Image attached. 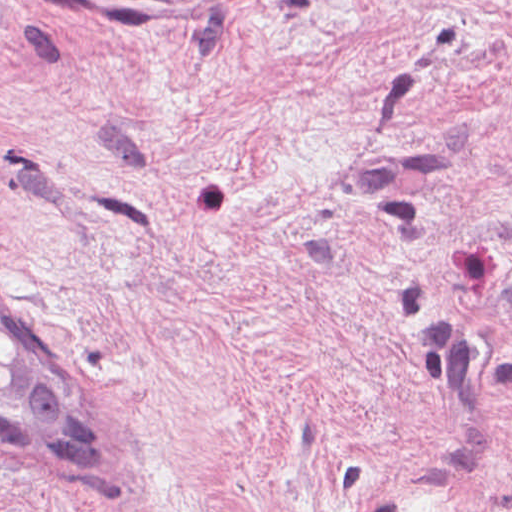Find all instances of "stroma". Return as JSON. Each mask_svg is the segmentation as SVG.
Returning a JSON list of instances; mask_svg holds the SVG:
<instances>
[{
    "mask_svg": "<svg viewBox=\"0 0 512 512\" xmlns=\"http://www.w3.org/2000/svg\"><path fill=\"white\" fill-rule=\"evenodd\" d=\"M0 285V512H512V0H0Z\"/></svg>",
    "mask_w": 512,
    "mask_h": 512,
    "instance_id": "stroma-1",
    "label": "stroma"
}]
</instances>
